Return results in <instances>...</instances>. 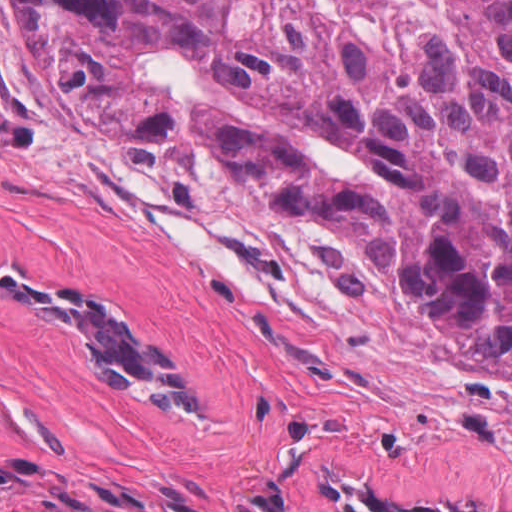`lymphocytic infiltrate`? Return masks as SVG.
Listing matches in <instances>:
<instances>
[{
	"mask_svg": "<svg viewBox=\"0 0 512 512\" xmlns=\"http://www.w3.org/2000/svg\"><path fill=\"white\" fill-rule=\"evenodd\" d=\"M42 476V472L4 470L0 468V498L11 496L28 489Z\"/></svg>",
	"mask_w": 512,
	"mask_h": 512,
	"instance_id": "lymphocytic-infiltrate-1",
	"label": "lymphocytic infiltrate"
}]
</instances>
